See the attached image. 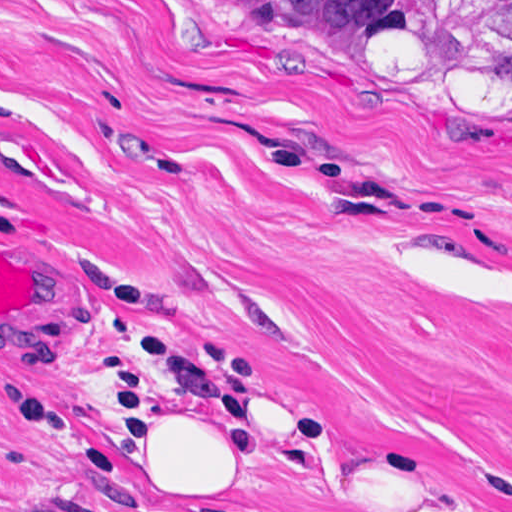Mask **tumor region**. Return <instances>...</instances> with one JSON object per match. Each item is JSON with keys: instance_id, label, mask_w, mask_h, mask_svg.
Returning <instances> with one entry per match:
<instances>
[{"instance_id": "e687c5a6", "label": "tumor region", "mask_w": 512, "mask_h": 512, "mask_svg": "<svg viewBox=\"0 0 512 512\" xmlns=\"http://www.w3.org/2000/svg\"><path fill=\"white\" fill-rule=\"evenodd\" d=\"M241 1L288 48L353 84L512 105V0Z\"/></svg>"}]
</instances>
